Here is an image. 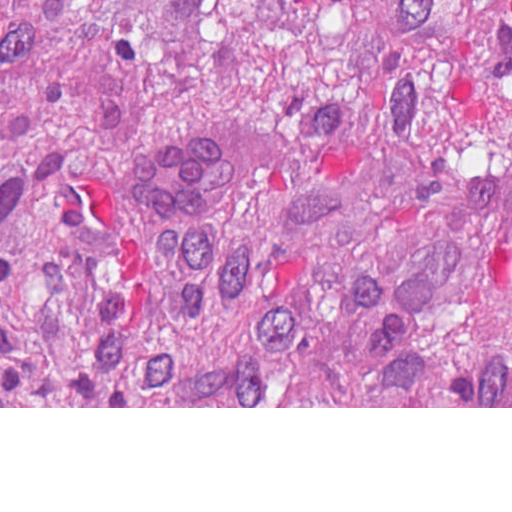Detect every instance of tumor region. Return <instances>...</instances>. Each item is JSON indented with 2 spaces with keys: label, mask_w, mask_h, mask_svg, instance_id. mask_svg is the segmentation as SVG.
Instances as JSON below:
<instances>
[{
  "label": "tumor region",
  "mask_w": 512,
  "mask_h": 512,
  "mask_svg": "<svg viewBox=\"0 0 512 512\" xmlns=\"http://www.w3.org/2000/svg\"><path fill=\"white\" fill-rule=\"evenodd\" d=\"M0 406L512 407V0H0Z\"/></svg>",
  "instance_id": "obj_1"
}]
</instances>
